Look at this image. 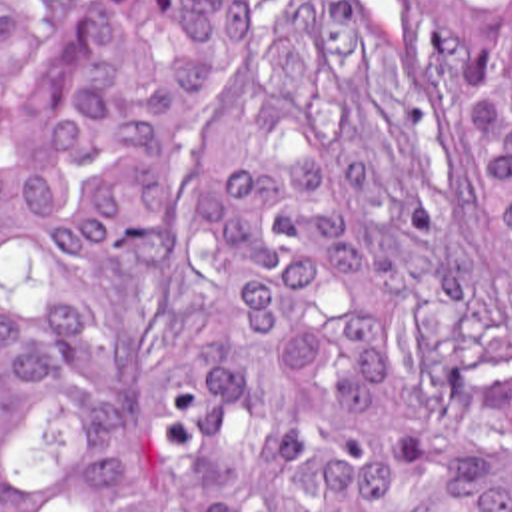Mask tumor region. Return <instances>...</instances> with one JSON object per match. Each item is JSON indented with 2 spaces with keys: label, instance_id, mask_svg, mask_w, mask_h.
I'll return each instance as SVG.
<instances>
[{
  "label": "tumor region",
  "instance_id": "tumor-region-1",
  "mask_svg": "<svg viewBox=\"0 0 512 512\" xmlns=\"http://www.w3.org/2000/svg\"><path fill=\"white\" fill-rule=\"evenodd\" d=\"M440 87L354 0H0V512H512V0Z\"/></svg>",
  "mask_w": 512,
  "mask_h": 512
}]
</instances>
